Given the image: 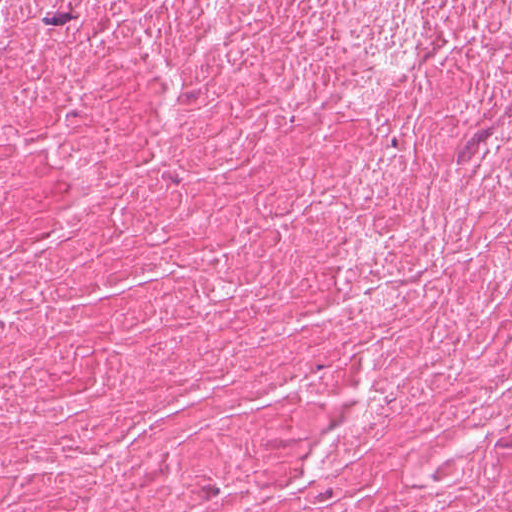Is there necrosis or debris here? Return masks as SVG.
<instances>
[{
  "label": "necrosis or debris",
  "mask_w": 512,
  "mask_h": 512,
  "mask_svg": "<svg viewBox=\"0 0 512 512\" xmlns=\"http://www.w3.org/2000/svg\"><path fill=\"white\" fill-rule=\"evenodd\" d=\"M0 512H512V0H0Z\"/></svg>",
  "instance_id": "1"
}]
</instances>
